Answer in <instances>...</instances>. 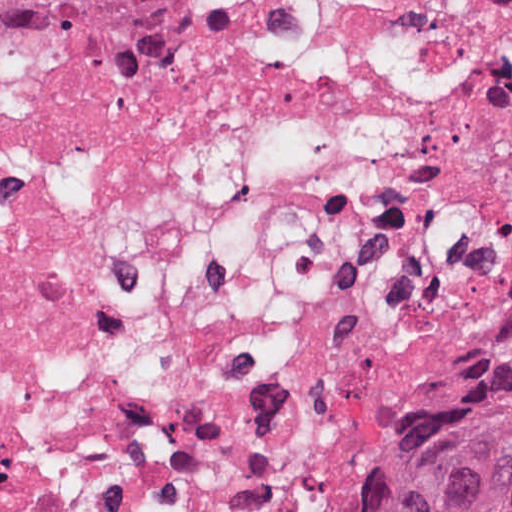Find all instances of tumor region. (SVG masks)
Returning <instances> with one entry per match:
<instances>
[{
    "instance_id": "e687c5a6",
    "label": "tumor region",
    "mask_w": 512,
    "mask_h": 512,
    "mask_svg": "<svg viewBox=\"0 0 512 512\" xmlns=\"http://www.w3.org/2000/svg\"><path fill=\"white\" fill-rule=\"evenodd\" d=\"M228 0H0V58L86 28H194ZM372 512H512V348L379 488Z\"/></svg>"
}]
</instances>
